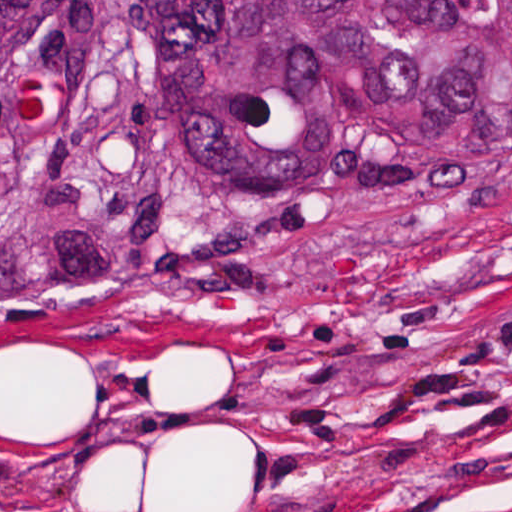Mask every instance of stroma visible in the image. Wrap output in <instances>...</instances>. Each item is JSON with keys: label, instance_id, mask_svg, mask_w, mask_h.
I'll return each instance as SVG.
<instances>
[{"label": "stroma", "instance_id": "stroma-1", "mask_svg": "<svg viewBox=\"0 0 512 512\" xmlns=\"http://www.w3.org/2000/svg\"><path fill=\"white\" fill-rule=\"evenodd\" d=\"M0 512H512V188L190 220L0 308Z\"/></svg>", "mask_w": 512, "mask_h": 512}]
</instances>
